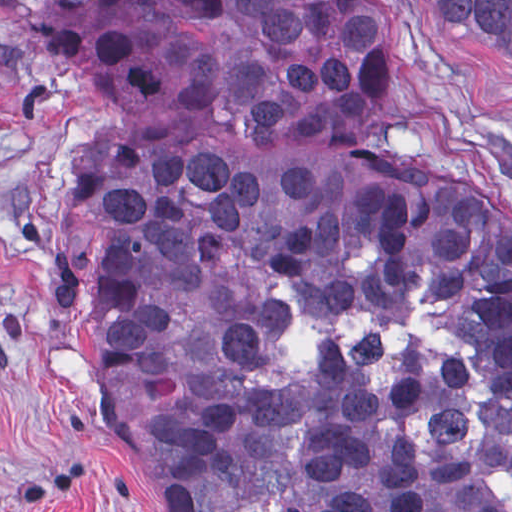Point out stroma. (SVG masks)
<instances>
[{
    "instance_id": "1",
    "label": "stroma",
    "mask_w": 512,
    "mask_h": 512,
    "mask_svg": "<svg viewBox=\"0 0 512 512\" xmlns=\"http://www.w3.org/2000/svg\"><path fill=\"white\" fill-rule=\"evenodd\" d=\"M94 0H0V512H160L109 454L97 368L53 296L74 160L97 99L59 63L57 21ZM399 154L425 186L512 210V82L397 0Z\"/></svg>"
}]
</instances>
